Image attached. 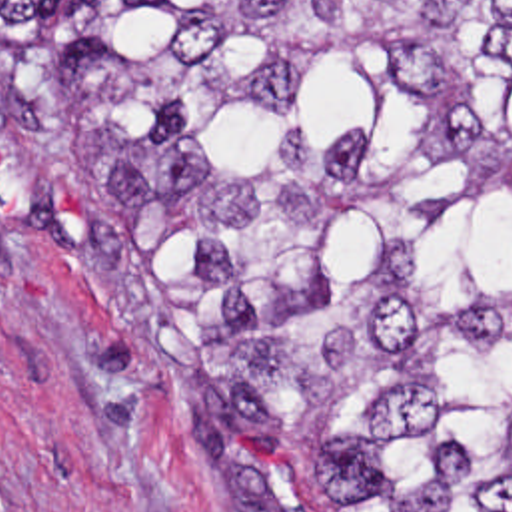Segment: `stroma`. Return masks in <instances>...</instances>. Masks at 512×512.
<instances>
[{
    "label": "stroma",
    "mask_w": 512,
    "mask_h": 512,
    "mask_svg": "<svg viewBox=\"0 0 512 512\" xmlns=\"http://www.w3.org/2000/svg\"><path fill=\"white\" fill-rule=\"evenodd\" d=\"M225 360L77 179L0 0V512H223L197 368Z\"/></svg>",
    "instance_id": "1"
}]
</instances>
